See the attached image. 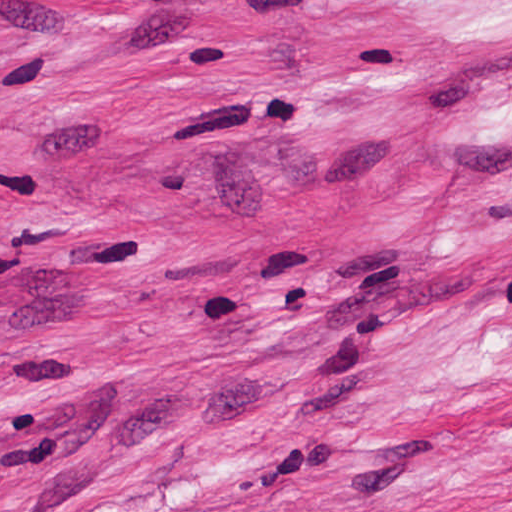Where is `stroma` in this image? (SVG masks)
Wrapping results in <instances>:
<instances>
[{"instance_id":"35a3bbf8","label":"stroma","mask_w":512,"mask_h":512,"mask_svg":"<svg viewBox=\"0 0 512 512\" xmlns=\"http://www.w3.org/2000/svg\"><path fill=\"white\" fill-rule=\"evenodd\" d=\"M0 512H512V0H0Z\"/></svg>"}]
</instances>
